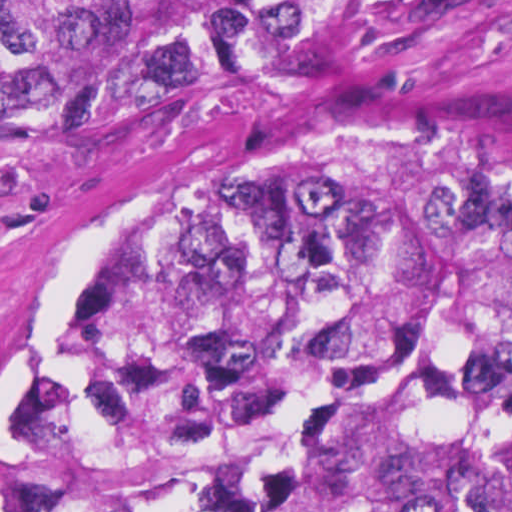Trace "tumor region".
<instances>
[{
	"mask_svg": "<svg viewBox=\"0 0 512 512\" xmlns=\"http://www.w3.org/2000/svg\"><path fill=\"white\" fill-rule=\"evenodd\" d=\"M378 0H0V183ZM0 512H512V165L273 144L111 238L0 401Z\"/></svg>",
	"mask_w": 512,
	"mask_h": 512,
	"instance_id": "tumor-region-1",
	"label": "tumor region"
}]
</instances>
